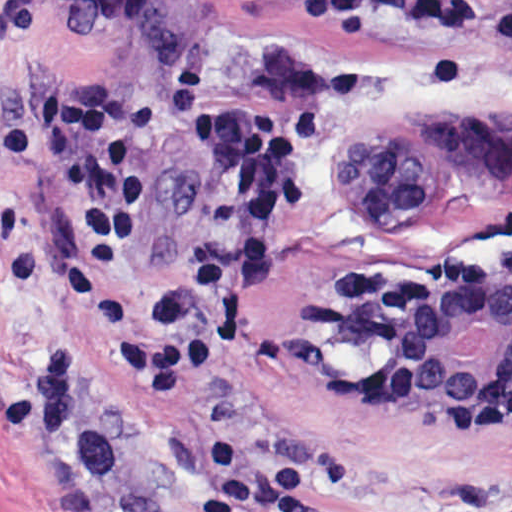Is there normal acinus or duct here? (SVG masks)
I'll use <instances>...</instances> for the list:
<instances>
[{
	"label": "normal acinus or duct",
	"instance_id": "30e58d81",
	"mask_svg": "<svg viewBox=\"0 0 512 512\" xmlns=\"http://www.w3.org/2000/svg\"><path fill=\"white\" fill-rule=\"evenodd\" d=\"M332 343L409 420L459 424L512 394V263L451 287L378 275L328 294Z\"/></svg>",
	"mask_w": 512,
	"mask_h": 512
}]
</instances>
